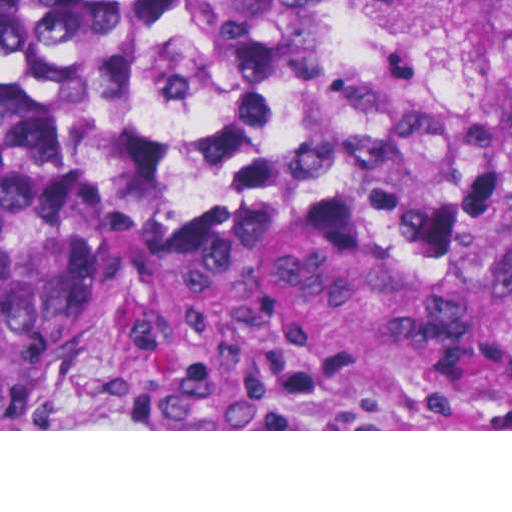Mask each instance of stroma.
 Instances as JSON below:
<instances>
[{
    "label": "stroma",
    "mask_w": 512,
    "mask_h": 512,
    "mask_svg": "<svg viewBox=\"0 0 512 512\" xmlns=\"http://www.w3.org/2000/svg\"><path fill=\"white\" fill-rule=\"evenodd\" d=\"M426 0H382L331 59L301 76L238 70L193 76L174 96H121L101 111L96 170L122 245L117 274L86 349L70 429L0 431H512V411L491 403L379 408L331 428H301L213 413L181 401L167 382V235L209 163L269 173L325 157L369 186L402 195L427 179L468 137L495 131L512 141V114H482L426 154L402 158L362 145H272L211 161L186 180L148 228L122 221L106 162L108 134L131 113L178 99H238L326 83L394 47Z\"/></svg>",
    "instance_id": "obj_1"
}]
</instances>
